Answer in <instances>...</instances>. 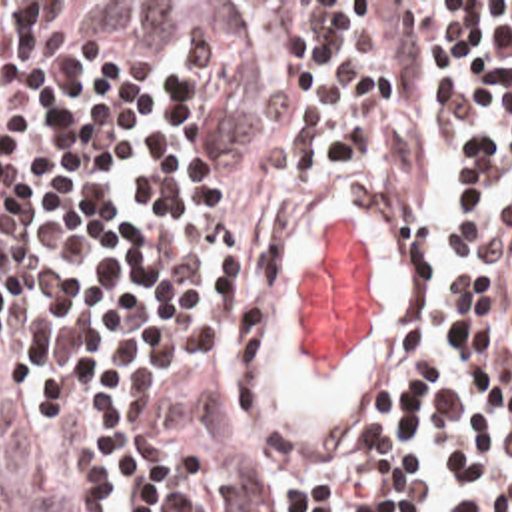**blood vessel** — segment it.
Wrapping results in <instances>:
<instances>
[{
	"label": "blood vessel",
	"instance_id": "obj_1",
	"mask_svg": "<svg viewBox=\"0 0 512 512\" xmlns=\"http://www.w3.org/2000/svg\"><path fill=\"white\" fill-rule=\"evenodd\" d=\"M426 307V212L358 172L245 258L227 327L229 401L273 473L340 463Z\"/></svg>",
	"mask_w": 512,
	"mask_h": 512
}]
</instances>
